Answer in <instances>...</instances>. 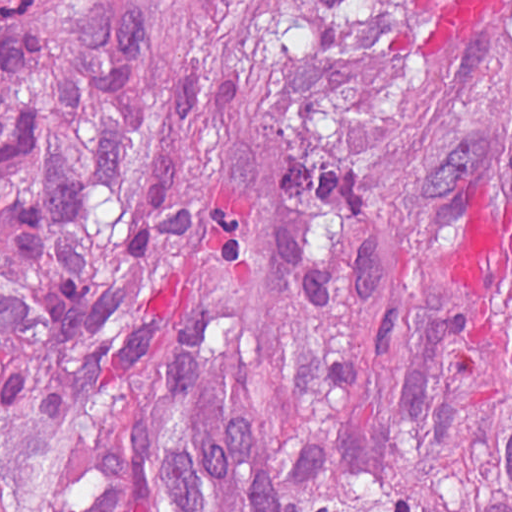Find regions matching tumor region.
Segmentation results:
<instances>
[{
    "label": "tumor region",
    "instance_id": "e687c5a6",
    "mask_svg": "<svg viewBox=\"0 0 512 512\" xmlns=\"http://www.w3.org/2000/svg\"><path fill=\"white\" fill-rule=\"evenodd\" d=\"M0 512H512V0H0Z\"/></svg>",
    "mask_w": 512,
    "mask_h": 512
}]
</instances>
